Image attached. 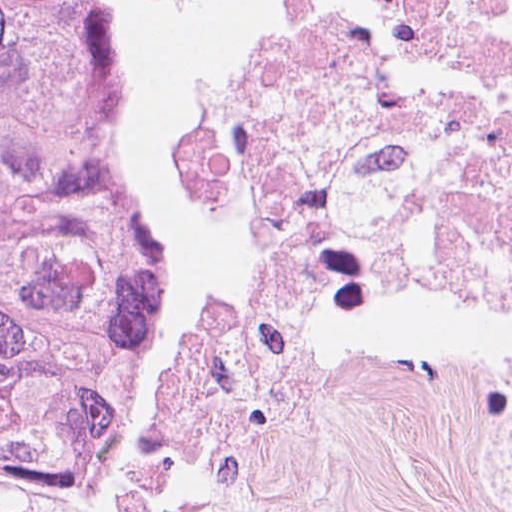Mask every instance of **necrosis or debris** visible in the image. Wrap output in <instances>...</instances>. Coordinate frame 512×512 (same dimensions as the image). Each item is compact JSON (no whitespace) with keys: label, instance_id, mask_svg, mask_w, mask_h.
Segmentation results:
<instances>
[{"label":"necrosis or debris","instance_id":"necrosis-or-debris-1","mask_svg":"<svg viewBox=\"0 0 512 512\" xmlns=\"http://www.w3.org/2000/svg\"><path fill=\"white\" fill-rule=\"evenodd\" d=\"M227 103V199L290 275H437L512 323V0H145ZM512 510V377L478 383Z\"/></svg>","mask_w":512,"mask_h":512}]
</instances>
